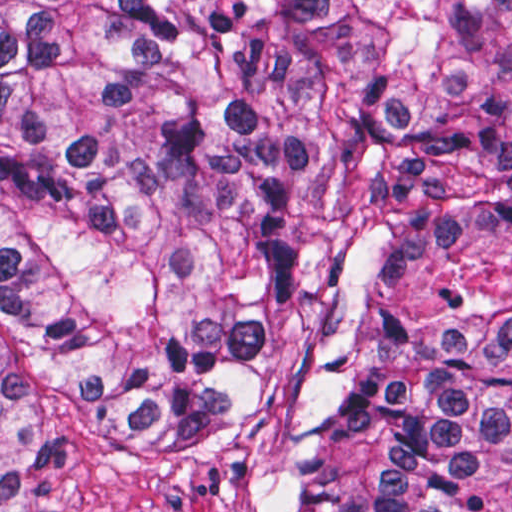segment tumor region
Masks as SVG:
<instances>
[{
	"mask_svg": "<svg viewBox=\"0 0 512 512\" xmlns=\"http://www.w3.org/2000/svg\"><path fill=\"white\" fill-rule=\"evenodd\" d=\"M143 418L265 512H512V0H0V512Z\"/></svg>",
	"mask_w": 512,
	"mask_h": 512,
	"instance_id": "1",
	"label": "tumor region"
}]
</instances>
